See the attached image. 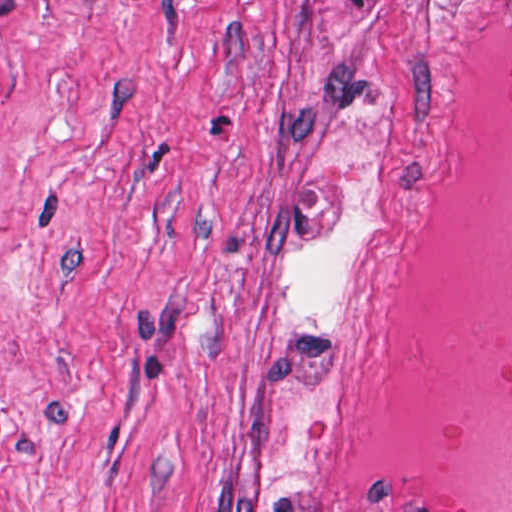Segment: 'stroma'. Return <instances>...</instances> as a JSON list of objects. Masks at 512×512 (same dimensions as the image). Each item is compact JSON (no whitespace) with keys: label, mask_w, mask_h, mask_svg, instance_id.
Listing matches in <instances>:
<instances>
[{"label":"stroma","mask_w":512,"mask_h":512,"mask_svg":"<svg viewBox=\"0 0 512 512\" xmlns=\"http://www.w3.org/2000/svg\"><path fill=\"white\" fill-rule=\"evenodd\" d=\"M439 0H0V512H360L321 319Z\"/></svg>","instance_id":"35a3bbf8"}]
</instances>
